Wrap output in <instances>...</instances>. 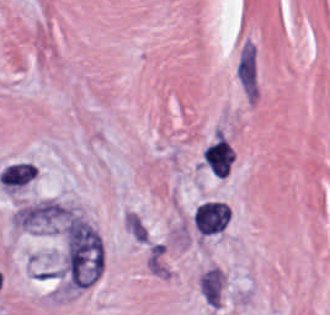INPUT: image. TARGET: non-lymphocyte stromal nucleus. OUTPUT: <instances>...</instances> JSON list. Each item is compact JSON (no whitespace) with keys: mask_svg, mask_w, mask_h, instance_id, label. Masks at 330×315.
<instances>
[{"mask_svg":"<svg viewBox=\"0 0 330 315\" xmlns=\"http://www.w3.org/2000/svg\"><path fill=\"white\" fill-rule=\"evenodd\" d=\"M103 269L100 235L83 219L70 216L66 220L65 272L67 288L89 284Z\"/></svg>","mask_w":330,"mask_h":315,"instance_id":"1","label":"non-lymphocyte stromal nucleus"},{"mask_svg":"<svg viewBox=\"0 0 330 315\" xmlns=\"http://www.w3.org/2000/svg\"><path fill=\"white\" fill-rule=\"evenodd\" d=\"M230 159V144L221 138L203 151V161L219 177H226L230 169Z\"/></svg>","mask_w":330,"mask_h":315,"instance_id":"3","label":"non-lymphocyte stromal nucleus"},{"mask_svg":"<svg viewBox=\"0 0 330 315\" xmlns=\"http://www.w3.org/2000/svg\"><path fill=\"white\" fill-rule=\"evenodd\" d=\"M227 224L228 205L220 200H206L193 213V225L200 236H216Z\"/></svg>","mask_w":330,"mask_h":315,"instance_id":"2","label":"non-lymphocyte stromal nucleus"},{"mask_svg":"<svg viewBox=\"0 0 330 315\" xmlns=\"http://www.w3.org/2000/svg\"><path fill=\"white\" fill-rule=\"evenodd\" d=\"M36 167L25 162L9 163L0 172V184L4 187H22L31 180Z\"/></svg>","mask_w":330,"mask_h":315,"instance_id":"4","label":"non-lymphocyte stromal nucleus"}]
</instances>
